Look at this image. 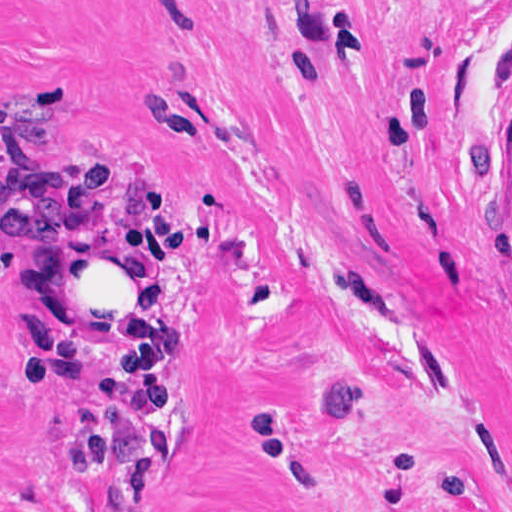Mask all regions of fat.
Listing matches in <instances>:
<instances>
[{
    "label": "fat",
    "instance_id": "1",
    "mask_svg": "<svg viewBox=\"0 0 512 512\" xmlns=\"http://www.w3.org/2000/svg\"><path fill=\"white\" fill-rule=\"evenodd\" d=\"M176 291L173 246L144 234H105L41 269V305L118 375L161 365Z\"/></svg>",
    "mask_w": 512,
    "mask_h": 512
}]
</instances>
